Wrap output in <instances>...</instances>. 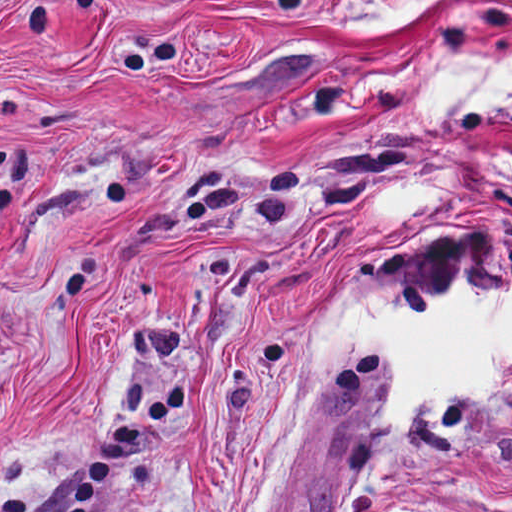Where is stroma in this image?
<instances>
[{"label":"stroma","mask_w":512,"mask_h":512,"mask_svg":"<svg viewBox=\"0 0 512 512\" xmlns=\"http://www.w3.org/2000/svg\"><path fill=\"white\" fill-rule=\"evenodd\" d=\"M0 0V512H239L330 313L512 290V103L419 123L426 56L512 59V0ZM441 193L382 215L392 188ZM387 357L339 373L280 512H512V375L379 477ZM379 451L366 481L372 452Z\"/></svg>","instance_id":"35a3bbf8"}]
</instances>
